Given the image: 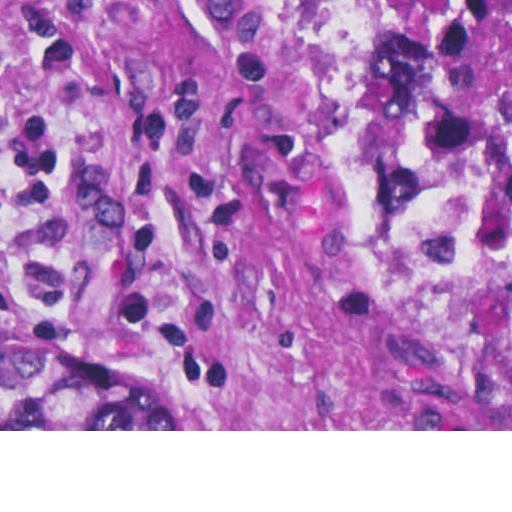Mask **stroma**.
I'll return each mask as SVG.
<instances>
[{"label": "stroma", "instance_id": "35a3bbf8", "mask_svg": "<svg viewBox=\"0 0 512 512\" xmlns=\"http://www.w3.org/2000/svg\"><path fill=\"white\" fill-rule=\"evenodd\" d=\"M297 148L258 0H0V431L461 429ZM1 339L157 371L183 429H1Z\"/></svg>", "mask_w": 512, "mask_h": 512}]
</instances>
